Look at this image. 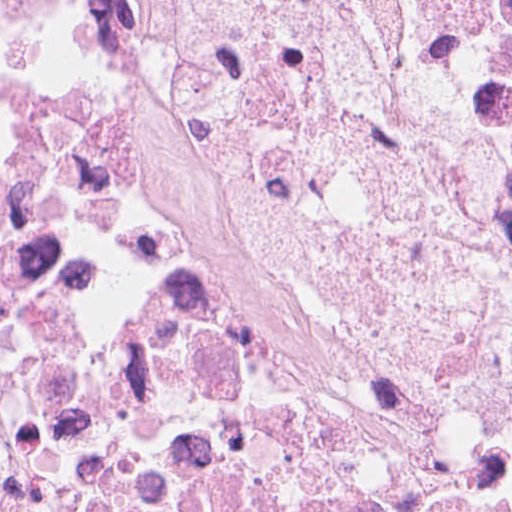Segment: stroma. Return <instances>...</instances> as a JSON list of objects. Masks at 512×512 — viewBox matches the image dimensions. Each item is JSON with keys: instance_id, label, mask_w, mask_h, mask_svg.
Instances as JSON below:
<instances>
[{"instance_id": "35a3bbf8", "label": "stroma", "mask_w": 512, "mask_h": 512, "mask_svg": "<svg viewBox=\"0 0 512 512\" xmlns=\"http://www.w3.org/2000/svg\"><path fill=\"white\" fill-rule=\"evenodd\" d=\"M166 171L246 247L391 334L430 383L512 437V291L477 265L422 253L346 178L334 127V15L301 61V145L259 169L214 141L168 77L108 29L104 0H37Z\"/></svg>"}]
</instances>
